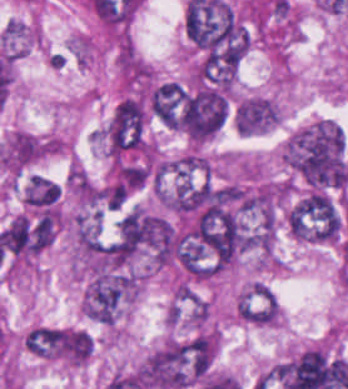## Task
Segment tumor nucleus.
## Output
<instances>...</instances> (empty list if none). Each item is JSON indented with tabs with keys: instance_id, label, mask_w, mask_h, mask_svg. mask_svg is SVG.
I'll use <instances>...</instances> for the list:
<instances>
[{
	"instance_id": "9",
	"label": "tumor nucleus",
	"mask_w": 348,
	"mask_h": 389,
	"mask_svg": "<svg viewBox=\"0 0 348 389\" xmlns=\"http://www.w3.org/2000/svg\"><path fill=\"white\" fill-rule=\"evenodd\" d=\"M24 346L36 357L57 359L60 347L56 327L35 326L27 333Z\"/></svg>"
},
{
	"instance_id": "8",
	"label": "tumor nucleus",
	"mask_w": 348,
	"mask_h": 389,
	"mask_svg": "<svg viewBox=\"0 0 348 389\" xmlns=\"http://www.w3.org/2000/svg\"><path fill=\"white\" fill-rule=\"evenodd\" d=\"M60 196V184L46 175L33 174L23 187L25 205L41 213L57 210Z\"/></svg>"
},
{
	"instance_id": "4",
	"label": "tumor nucleus",
	"mask_w": 348,
	"mask_h": 389,
	"mask_svg": "<svg viewBox=\"0 0 348 389\" xmlns=\"http://www.w3.org/2000/svg\"><path fill=\"white\" fill-rule=\"evenodd\" d=\"M287 227L294 239L333 243L337 229L335 204L324 189L309 188L290 206Z\"/></svg>"
},
{
	"instance_id": "2",
	"label": "tumor nucleus",
	"mask_w": 348,
	"mask_h": 389,
	"mask_svg": "<svg viewBox=\"0 0 348 389\" xmlns=\"http://www.w3.org/2000/svg\"><path fill=\"white\" fill-rule=\"evenodd\" d=\"M215 349L216 339L210 332L169 338L143 363L145 387L189 388L208 369Z\"/></svg>"
},
{
	"instance_id": "10",
	"label": "tumor nucleus",
	"mask_w": 348,
	"mask_h": 389,
	"mask_svg": "<svg viewBox=\"0 0 348 389\" xmlns=\"http://www.w3.org/2000/svg\"><path fill=\"white\" fill-rule=\"evenodd\" d=\"M34 40V24L16 17H9L0 31V44L6 50H26Z\"/></svg>"
},
{
	"instance_id": "3",
	"label": "tumor nucleus",
	"mask_w": 348,
	"mask_h": 389,
	"mask_svg": "<svg viewBox=\"0 0 348 389\" xmlns=\"http://www.w3.org/2000/svg\"><path fill=\"white\" fill-rule=\"evenodd\" d=\"M138 294L133 272L98 269L89 274L81 295V314L99 322L114 323Z\"/></svg>"
},
{
	"instance_id": "5",
	"label": "tumor nucleus",
	"mask_w": 348,
	"mask_h": 389,
	"mask_svg": "<svg viewBox=\"0 0 348 389\" xmlns=\"http://www.w3.org/2000/svg\"><path fill=\"white\" fill-rule=\"evenodd\" d=\"M146 109L138 96L120 98L107 122L108 150H140L144 142Z\"/></svg>"
},
{
	"instance_id": "1",
	"label": "tumor nucleus",
	"mask_w": 348,
	"mask_h": 389,
	"mask_svg": "<svg viewBox=\"0 0 348 389\" xmlns=\"http://www.w3.org/2000/svg\"><path fill=\"white\" fill-rule=\"evenodd\" d=\"M279 155L312 185L342 186L348 178L343 134L333 121L317 119L296 128L284 139Z\"/></svg>"
},
{
	"instance_id": "6",
	"label": "tumor nucleus",
	"mask_w": 348,
	"mask_h": 389,
	"mask_svg": "<svg viewBox=\"0 0 348 389\" xmlns=\"http://www.w3.org/2000/svg\"><path fill=\"white\" fill-rule=\"evenodd\" d=\"M186 93L181 84L173 81L153 83L147 95L150 116L167 127H180Z\"/></svg>"
},
{
	"instance_id": "7",
	"label": "tumor nucleus",
	"mask_w": 348,
	"mask_h": 389,
	"mask_svg": "<svg viewBox=\"0 0 348 389\" xmlns=\"http://www.w3.org/2000/svg\"><path fill=\"white\" fill-rule=\"evenodd\" d=\"M236 311L249 324L273 325L278 320V305L262 282L254 281L236 298Z\"/></svg>"
}]
</instances>
